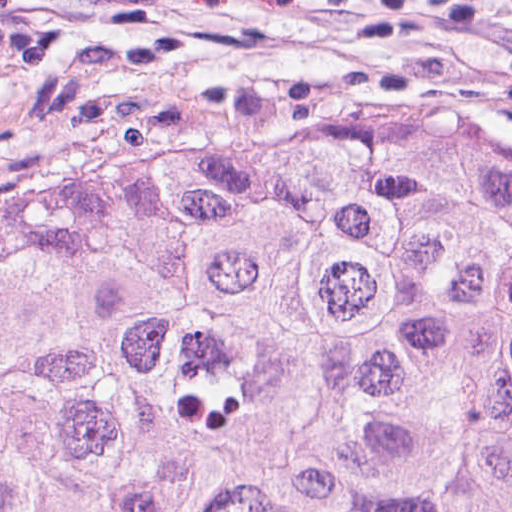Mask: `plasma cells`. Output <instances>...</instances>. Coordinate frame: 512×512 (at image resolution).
Returning <instances> with one entry per match:
<instances>
[{"label":"plasma cells","mask_w":512,"mask_h":512,"mask_svg":"<svg viewBox=\"0 0 512 512\" xmlns=\"http://www.w3.org/2000/svg\"><path fill=\"white\" fill-rule=\"evenodd\" d=\"M472 25L512 41V0H450Z\"/></svg>","instance_id":"1"}]
</instances>
